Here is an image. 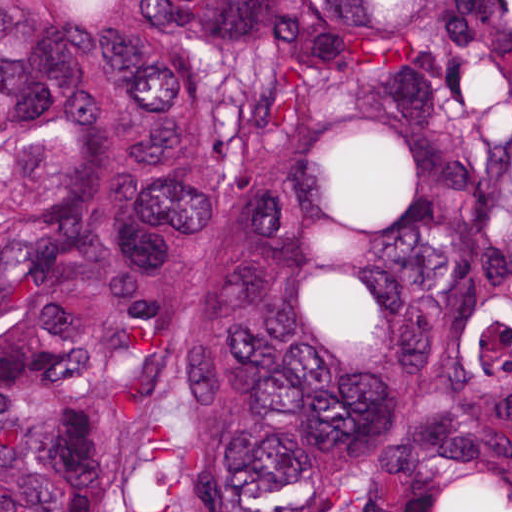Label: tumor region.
<instances>
[{"mask_svg":"<svg viewBox=\"0 0 512 512\" xmlns=\"http://www.w3.org/2000/svg\"><path fill=\"white\" fill-rule=\"evenodd\" d=\"M0 512H512V0H0Z\"/></svg>","mask_w":512,"mask_h":512,"instance_id":"1","label":"tumor region"}]
</instances>
